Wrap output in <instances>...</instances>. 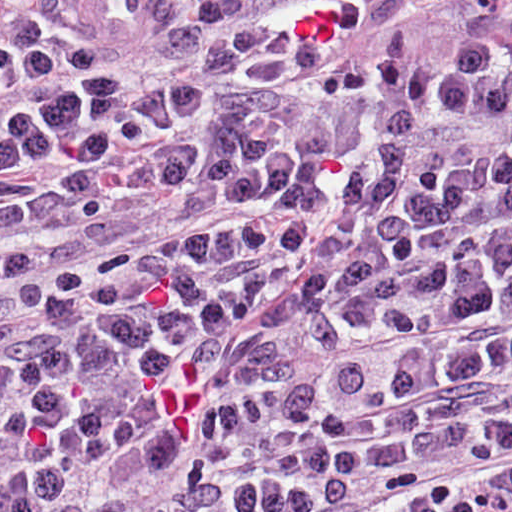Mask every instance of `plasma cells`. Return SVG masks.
Here are the masks:
<instances>
[{"label":"plasma cells","instance_id":"plasma-cells-1","mask_svg":"<svg viewBox=\"0 0 512 512\" xmlns=\"http://www.w3.org/2000/svg\"><path fill=\"white\" fill-rule=\"evenodd\" d=\"M0 512H512V9L0 4Z\"/></svg>","mask_w":512,"mask_h":512}]
</instances>
